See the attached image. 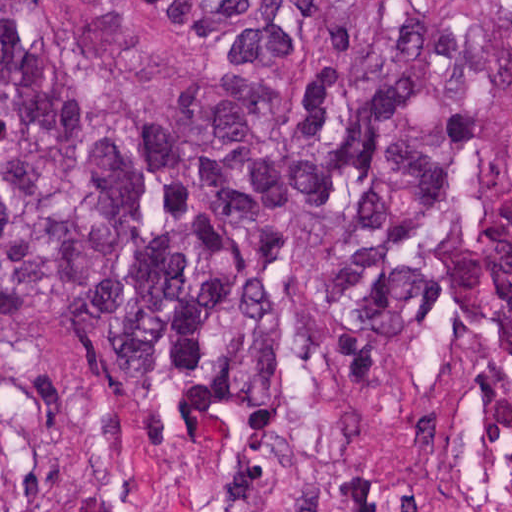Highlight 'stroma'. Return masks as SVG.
<instances>
[{"mask_svg":"<svg viewBox=\"0 0 512 512\" xmlns=\"http://www.w3.org/2000/svg\"><path fill=\"white\" fill-rule=\"evenodd\" d=\"M73 26L91 0H52ZM0 456L25 512H256L275 480L328 474L377 506L512 481V377L445 314L396 341L348 337L290 286L280 373L204 431H153L102 337L0 327Z\"/></svg>","mask_w":512,"mask_h":512,"instance_id":"1","label":"stroma"}]
</instances>
